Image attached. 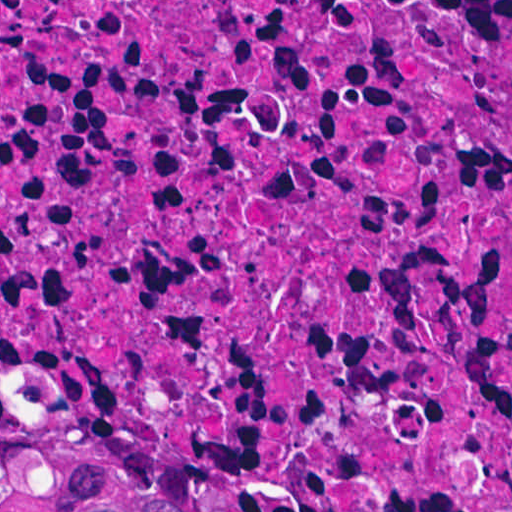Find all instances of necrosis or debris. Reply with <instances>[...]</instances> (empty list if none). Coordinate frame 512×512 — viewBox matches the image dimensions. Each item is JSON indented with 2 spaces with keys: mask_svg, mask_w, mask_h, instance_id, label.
<instances>
[{
  "mask_svg": "<svg viewBox=\"0 0 512 512\" xmlns=\"http://www.w3.org/2000/svg\"><path fill=\"white\" fill-rule=\"evenodd\" d=\"M0 404L243 512H512V0H0Z\"/></svg>",
  "mask_w": 512,
  "mask_h": 512,
  "instance_id": "4bbe7bcc",
  "label": "necrosis or debris"
}]
</instances>
